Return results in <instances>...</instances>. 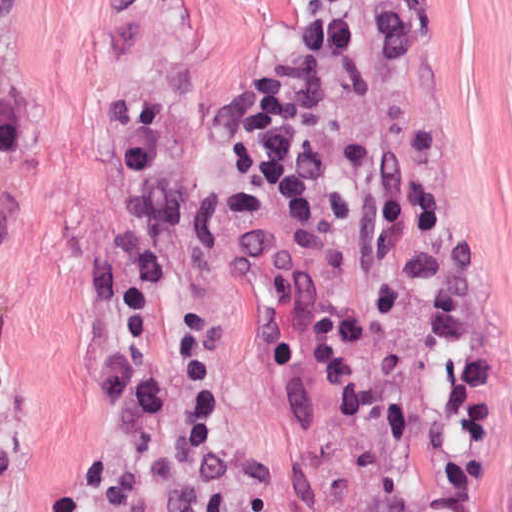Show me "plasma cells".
<instances>
[{"label":"plasma cells","mask_w":512,"mask_h":512,"mask_svg":"<svg viewBox=\"0 0 512 512\" xmlns=\"http://www.w3.org/2000/svg\"><path fill=\"white\" fill-rule=\"evenodd\" d=\"M164 104L113 97L105 105L110 148L127 167L117 243L92 272L87 286L105 303L144 312L164 270V247L148 206L163 141ZM23 154V131L12 88V59L0 29V157Z\"/></svg>","instance_id":"1"}]
</instances>
